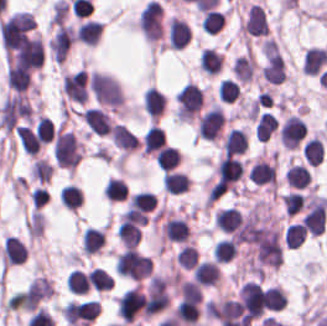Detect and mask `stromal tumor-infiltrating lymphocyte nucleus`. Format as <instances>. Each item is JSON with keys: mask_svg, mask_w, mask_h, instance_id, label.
<instances>
[{"mask_svg": "<svg viewBox=\"0 0 327 326\" xmlns=\"http://www.w3.org/2000/svg\"><path fill=\"white\" fill-rule=\"evenodd\" d=\"M226 116L219 103H212L198 117L196 132L201 139L216 140L221 137Z\"/></svg>", "mask_w": 327, "mask_h": 326, "instance_id": "bc302bb0", "label": "stromal tumor-infiltrating lymphocyte nucleus"}, {"mask_svg": "<svg viewBox=\"0 0 327 326\" xmlns=\"http://www.w3.org/2000/svg\"><path fill=\"white\" fill-rule=\"evenodd\" d=\"M306 127L299 115L289 113L279 126V142L284 148H297L305 137Z\"/></svg>", "mask_w": 327, "mask_h": 326, "instance_id": "52c7bb5b", "label": "stromal tumor-infiltrating lymphocyte nucleus"}, {"mask_svg": "<svg viewBox=\"0 0 327 326\" xmlns=\"http://www.w3.org/2000/svg\"><path fill=\"white\" fill-rule=\"evenodd\" d=\"M267 28L263 8L258 3H251L239 25V32L243 35H266Z\"/></svg>", "mask_w": 327, "mask_h": 326, "instance_id": "3290ff9b", "label": "stromal tumor-infiltrating lymphocyte nucleus"}, {"mask_svg": "<svg viewBox=\"0 0 327 326\" xmlns=\"http://www.w3.org/2000/svg\"><path fill=\"white\" fill-rule=\"evenodd\" d=\"M165 134L157 123H150L141 137L143 154L160 164Z\"/></svg>", "mask_w": 327, "mask_h": 326, "instance_id": "abfb95fc", "label": "stromal tumor-infiltrating lymphocyte nucleus"}, {"mask_svg": "<svg viewBox=\"0 0 327 326\" xmlns=\"http://www.w3.org/2000/svg\"><path fill=\"white\" fill-rule=\"evenodd\" d=\"M221 271L217 261L202 258L191 269V279L201 286L218 284Z\"/></svg>", "mask_w": 327, "mask_h": 326, "instance_id": "9ea309e8", "label": "stromal tumor-infiltrating lymphocyte nucleus"}, {"mask_svg": "<svg viewBox=\"0 0 327 326\" xmlns=\"http://www.w3.org/2000/svg\"><path fill=\"white\" fill-rule=\"evenodd\" d=\"M81 119L88 131L94 134H108L113 125L107 113L98 107H84Z\"/></svg>", "mask_w": 327, "mask_h": 326, "instance_id": "f3e2335f", "label": "stromal tumor-infiltrating lymphocyte nucleus"}, {"mask_svg": "<svg viewBox=\"0 0 327 326\" xmlns=\"http://www.w3.org/2000/svg\"><path fill=\"white\" fill-rule=\"evenodd\" d=\"M26 254V246L18 237L6 235L0 249V264L9 267L20 264Z\"/></svg>", "mask_w": 327, "mask_h": 326, "instance_id": "4f13568d", "label": "stromal tumor-infiltrating lymphocyte nucleus"}, {"mask_svg": "<svg viewBox=\"0 0 327 326\" xmlns=\"http://www.w3.org/2000/svg\"><path fill=\"white\" fill-rule=\"evenodd\" d=\"M188 41V23L176 16L166 20V44L174 48H182Z\"/></svg>", "mask_w": 327, "mask_h": 326, "instance_id": "2a367800", "label": "stromal tumor-infiltrating lymphocyte nucleus"}, {"mask_svg": "<svg viewBox=\"0 0 327 326\" xmlns=\"http://www.w3.org/2000/svg\"><path fill=\"white\" fill-rule=\"evenodd\" d=\"M231 73L236 81L248 82L255 71V60L252 54L247 50L236 56L230 66Z\"/></svg>", "mask_w": 327, "mask_h": 326, "instance_id": "4803ca6d", "label": "stromal tumor-infiltrating lymphocyte nucleus"}, {"mask_svg": "<svg viewBox=\"0 0 327 326\" xmlns=\"http://www.w3.org/2000/svg\"><path fill=\"white\" fill-rule=\"evenodd\" d=\"M224 153H243L248 146V137L244 127H231L225 132L221 141Z\"/></svg>", "mask_w": 327, "mask_h": 326, "instance_id": "4245b91a", "label": "stromal tumor-infiltrating lymphocyte nucleus"}, {"mask_svg": "<svg viewBox=\"0 0 327 326\" xmlns=\"http://www.w3.org/2000/svg\"><path fill=\"white\" fill-rule=\"evenodd\" d=\"M101 31L99 21L84 19L79 21L74 32L73 41L88 45H94Z\"/></svg>", "mask_w": 327, "mask_h": 326, "instance_id": "4c9ddf68", "label": "stromal tumor-infiltrating lymphocyte nucleus"}, {"mask_svg": "<svg viewBox=\"0 0 327 326\" xmlns=\"http://www.w3.org/2000/svg\"><path fill=\"white\" fill-rule=\"evenodd\" d=\"M327 63V50L309 46L303 54V72L308 75H316Z\"/></svg>", "mask_w": 327, "mask_h": 326, "instance_id": "2761f720", "label": "stromal tumor-infiltrating lymphocyte nucleus"}, {"mask_svg": "<svg viewBox=\"0 0 327 326\" xmlns=\"http://www.w3.org/2000/svg\"><path fill=\"white\" fill-rule=\"evenodd\" d=\"M110 136L112 143L125 154L135 150L137 146L136 134L121 123H114Z\"/></svg>", "mask_w": 327, "mask_h": 326, "instance_id": "3c572f05", "label": "stromal tumor-infiltrating lymphocyte nucleus"}, {"mask_svg": "<svg viewBox=\"0 0 327 326\" xmlns=\"http://www.w3.org/2000/svg\"><path fill=\"white\" fill-rule=\"evenodd\" d=\"M240 221V211L233 206L220 207L213 215V227L234 232Z\"/></svg>", "mask_w": 327, "mask_h": 326, "instance_id": "42bb06b2", "label": "stromal tumor-infiltrating lymphocyte nucleus"}, {"mask_svg": "<svg viewBox=\"0 0 327 326\" xmlns=\"http://www.w3.org/2000/svg\"><path fill=\"white\" fill-rule=\"evenodd\" d=\"M83 256H90L99 251L104 244V231L100 227L86 226L81 232Z\"/></svg>", "mask_w": 327, "mask_h": 326, "instance_id": "9e4306bb", "label": "stromal tumor-infiltrating lymphocyte nucleus"}, {"mask_svg": "<svg viewBox=\"0 0 327 326\" xmlns=\"http://www.w3.org/2000/svg\"><path fill=\"white\" fill-rule=\"evenodd\" d=\"M162 189L170 194H178L190 186V178L186 171L170 170L162 176Z\"/></svg>", "mask_w": 327, "mask_h": 326, "instance_id": "04cf8593", "label": "stromal tumor-infiltrating lymphocyte nucleus"}, {"mask_svg": "<svg viewBox=\"0 0 327 326\" xmlns=\"http://www.w3.org/2000/svg\"><path fill=\"white\" fill-rule=\"evenodd\" d=\"M165 106L163 92L148 86L143 93V108L150 119H157Z\"/></svg>", "mask_w": 327, "mask_h": 326, "instance_id": "e9af9c67", "label": "stromal tumor-infiltrating lymphocyte nucleus"}, {"mask_svg": "<svg viewBox=\"0 0 327 326\" xmlns=\"http://www.w3.org/2000/svg\"><path fill=\"white\" fill-rule=\"evenodd\" d=\"M223 62V56L216 49L211 47H203L198 66L206 75H214L220 68Z\"/></svg>", "mask_w": 327, "mask_h": 326, "instance_id": "782c7336", "label": "stromal tumor-infiltrating lymphocyte nucleus"}, {"mask_svg": "<svg viewBox=\"0 0 327 326\" xmlns=\"http://www.w3.org/2000/svg\"><path fill=\"white\" fill-rule=\"evenodd\" d=\"M284 178L288 186L291 188L304 189L308 184L310 174L305 165L299 163H291Z\"/></svg>", "mask_w": 327, "mask_h": 326, "instance_id": "cac63f63", "label": "stromal tumor-infiltrating lymphocyte nucleus"}, {"mask_svg": "<svg viewBox=\"0 0 327 326\" xmlns=\"http://www.w3.org/2000/svg\"><path fill=\"white\" fill-rule=\"evenodd\" d=\"M238 254V243L229 237L219 239L212 251V258L217 262H227Z\"/></svg>", "mask_w": 327, "mask_h": 326, "instance_id": "2e467ee5", "label": "stromal tumor-infiltrating lymphocyte nucleus"}, {"mask_svg": "<svg viewBox=\"0 0 327 326\" xmlns=\"http://www.w3.org/2000/svg\"><path fill=\"white\" fill-rule=\"evenodd\" d=\"M102 193L104 195L105 200L109 201H119L125 200L128 190L126 188L125 183L115 177V176H108Z\"/></svg>", "mask_w": 327, "mask_h": 326, "instance_id": "7eef579d", "label": "stromal tumor-infiltrating lymphocyte nucleus"}, {"mask_svg": "<svg viewBox=\"0 0 327 326\" xmlns=\"http://www.w3.org/2000/svg\"><path fill=\"white\" fill-rule=\"evenodd\" d=\"M179 161L180 153L171 145H164L154 160L156 168L167 171L176 168Z\"/></svg>", "mask_w": 327, "mask_h": 326, "instance_id": "c26a33f6", "label": "stromal tumor-infiltrating lymphocyte nucleus"}, {"mask_svg": "<svg viewBox=\"0 0 327 326\" xmlns=\"http://www.w3.org/2000/svg\"><path fill=\"white\" fill-rule=\"evenodd\" d=\"M83 191L74 183L61 186V205L65 208L76 210L82 202Z\"/></svg>", "mask_w": 327, "mask_h": 326, "instance_id": "3e0999b9", "label": "stromal tumor-infiltrating lymphocyte nucleus"}, {"mask_svg": "<svg viewBox=\"0 0 327 326\" xmlns=\"http://www.w3.org/2000/svg\"><path fill=\"white\" fill-rule=\"evenodd\" d=\"M302 153L308 163V165H317L323 159V147L321 140L317 137H310L306 139L304 145L301 148Z\"/></svg>", "mask_w": 327, "mask_h": 326, "instance_id": "a0a3295f", "label": "stromal tumor-infiltrating lymphocyte nucleus"}, {"mask_svg": "<svg viewBox=\"0 0 327 326\" xmlns=\"http://www.w3.org/2000/svg\"><path fill=\"white\" fill-rule=\"evenodd\" d=\"M306 233L301 224L289 222L284 229L283 243L288 249H295L301 246Z\"/></svg>", "mask_w": 327, "mask_h": 326, "instance_id": "b6af03f8", "label": "stromal tumor-infiltrating lymphocyte nucleus"}, {"mask_svg": "<svg viewBox=\"0 0 327 326\" xmlns=\"http://www.w3.org/2000/svg\"><path fill=\"white\" fill-rule=\"evenodd\" d=\"M198 259L197 251L191 242H184L175 253L177 267L192 268Z\"/></svg>", "mask_w": 327, "mask_h": 326, "instance_id": "6c763739", "label": "stromal tumor-infiltrating lymphocyte nucleus"}, {"mask_svg": "<svg viewBox=\"0 0 327 326\" xmlns=\"http://www.w3.org/2000/svg\"><path fill=\"white\" fill-rule=\"evenodd\" d=\"M85 280L89 288L97 291H102L109 288L111 280L106 271L101 267H93L85 275Z\"/></svg>", "mask_w": 327, "mask_h": 326, "instance_id": "fa64b396", "label": "stromal tumor-infiltrating lymphocyte nucleus"}, {"mask_svg": "<svg viewBox=\"0 0 327 326\" xmlns=\"http://www.w3.org/2000/svg\"><path fill=\"white\" fill-rule=\"evenodd\" d=\"M280 201L282 203L285 215H294L305 205V196L299 191H291L280 194Z\"/></svg>", "mask_w": 327, "mask_h": 326, "instance_id": "21d57d70", "label": "stromal tumor-infiltrating lymphocyte nucleus"}, {"mask_svg": "<svg viewBox=\"0 0 327 326\" xmlns=\"http://www.w3.org/2000/svg\"><path fill=\"white\" fill-rule=\"evenodd\" d=\"M224 13L222 10L211 9L202 15L203 31L210 34H217L223 27Z\"/></svg>", "mask_w": 327, "mask_h": 326, "instance_id": "02f42fee", "label": "stromal tumor-infiltrating lymphocyte nucleus"}, {"mask_svg": "<svg viewBox=\"0 0 327 326\" xmlns=\"http://www.w3.org/2000/svg\"><path fill=\"white\" fill-rule=\"evenodd\" d=\"M217 92L222 101L234 102L240 96V87L230 77H223L218 83Z\"/></svg>", "mask_w": 327, "mask_h": 326, "instance_id": "18da8d3c", "label": "stromal tumor-infiltrating lymphocyte nucleus"}, {"mask_svg": "<svg viewBox=\"0 0 327 326\" xmlns=\"http://www.w3.org/2000/svg\"><path fill=\"white\" fill-rule=\"evenodd\" d=\"M65 283L71 293H85L87 289L84 273L78 268H71Z\"/></svg>", "mask_w": 327, "mask_h": 326, "instance_id": "8379cbfb", "label": "stromal tumor-infiltrating lymphocyte nucleus"}]
</instances>
